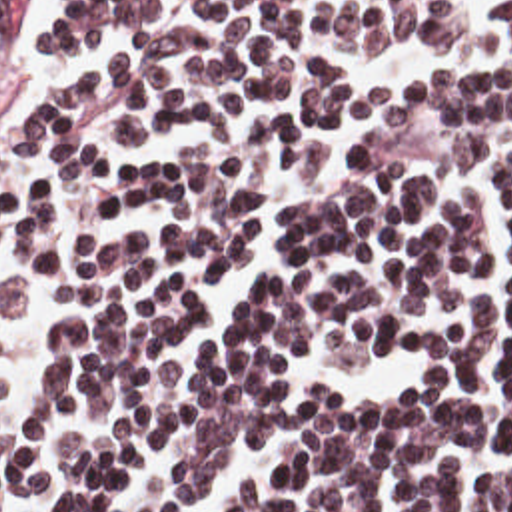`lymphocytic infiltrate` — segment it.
I'll return each mask as SVG.
<instances>
[{
  "instance_id": "lymphocytic-infiltrate-1",
  "label": "lymphocytic infiltrate",
  "mask_w": 512,
  "mask_h": 512,
  "mask_svg": "<svg viewBox=\"0 0 512 512\" xmlns=\"http://www.w3.org/2000/svg\"><path fill=\"white\" fill-rule=\"evenodd\" d=\"M26 6L0 0L6 36ZM489 18L487 60L354 92L302 40L450 44L462 0L66 6L38 60L128 56L0 126V254L30 258L8 314L50 322L0 512H182L268 432L278 468L222 512H454L465 456H512V1ZM410 352L378 398L300 388Z\"/></svg>"
}]
</instances>
